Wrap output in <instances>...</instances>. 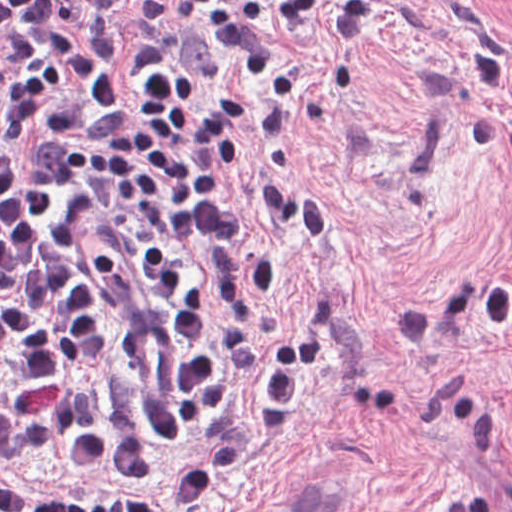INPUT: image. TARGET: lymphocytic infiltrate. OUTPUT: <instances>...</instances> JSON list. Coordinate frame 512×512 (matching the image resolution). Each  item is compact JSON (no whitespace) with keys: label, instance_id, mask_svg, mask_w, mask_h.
Listing matches in <instances>:
<instances>
[{"label":"lymphocytic infiltrate","instance_id":"lymphocytic-infiltrate-1","mask_svg":"<svg viewBox=\"0 0 512 512\" xmlns=\"http://www.w3.org/2000/svg\"><path fill=\"white\" fill-rule=\"evenodd\" d=\"M124 2L0 0V512H157L16 477L56 448L200 509L279 437L333 332L329 306L308 310L244 416L158 461L153 439L230 398L266 343L256 306L276 263L235 178H257L315 247L334 235L321 193L246 132L279 147L305 122L244 80L300 110L312 100L305 55L268 24L325 28L354 52L380 0H148L131 96L116 98Z\"/></svg>","mask_w":512,"mask_h":512}]
</instances>
